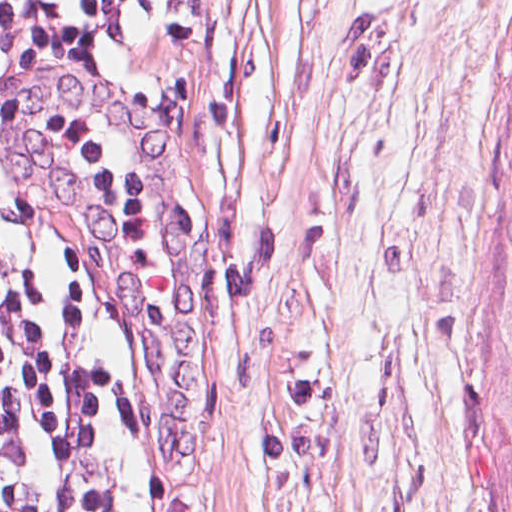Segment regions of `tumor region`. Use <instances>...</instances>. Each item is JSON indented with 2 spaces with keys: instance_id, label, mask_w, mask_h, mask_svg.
Returning <instances> with one entry per match:
<instances>
[{
  "instance_id": "obj_1",
  "label": "tumor region",
  "mask_w": 512,
  "mask_h": 512,
  "mask_svg": "<svg viewBox=\"0 0 512 512\" xmlns=\"http://www.w3.org/2000/svg\"><path fill=\"white\" fill-rule=\"evenodd\" d=\"M509 23L512 25V11ZM504 186L511 226V252L498 312L491 368L493 444L490 494L494 512H512V111L505 151Z\"/></svg>"
}]
</instances>
